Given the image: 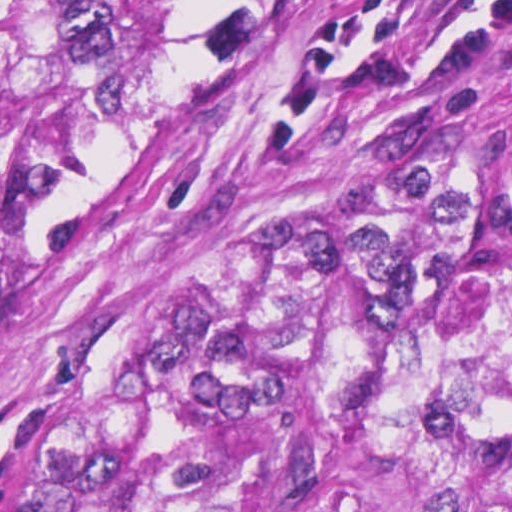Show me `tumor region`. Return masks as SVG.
<instances>
[{"instance_id": "e687c5a6", "label": "tumor region", "mask_w": 512, "mask_h": 512, "mask_svg": "<svg viewBox=\"0 0 512 512\" xmlns=\"http://www.w3.org/2000/svg\"><path fill=\"white\" fill-rule=\"evenodd\" d=\"M200 0H0V319ZM0 512H512V114L321 308L0 441Z\"/></svg>"}]
</instances>
